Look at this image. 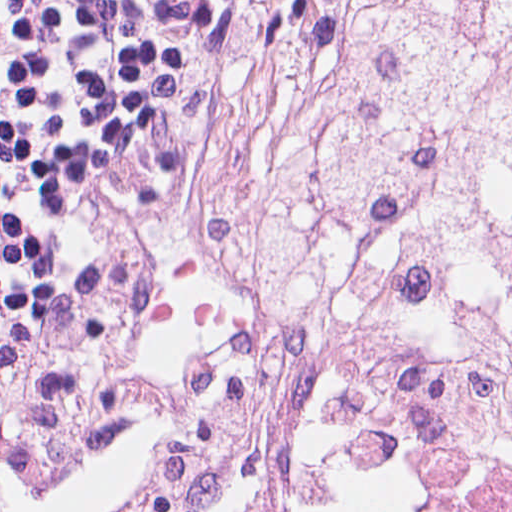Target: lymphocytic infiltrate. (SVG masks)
<instances>
[{"label":"lymphocytic infiltrate","instance_id":"1","mask_svg":"<svg viewBox=\"0 0 512 512\" xmlns=\"http://www.w3.org/2000/svg\"><path fill=\"white\" fill-rule=\"evenodd\" d=\"M224 22L220 0H0V352L119 211Z\"/></svg>","mask_w":512,"mask_h":512}]
</instances>
